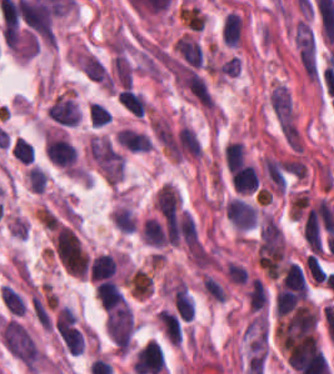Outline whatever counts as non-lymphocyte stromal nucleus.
<instances>
[{"instance_id": "obj_9", "label": "non-lymphocyte stromal nucleus", "mask_w": 334, "mask_h": 374, "mask_svg": "<svg viewBox=\"0 0 334 374\" xmlns=\"http://www.w3.org/2000/svg\"><path fill=\"white\" fill-rule=\"evenodd\" d=\"M261 163L271 192L282 196L291 169L290 162L265 155Z\"/></svg>"}, {"instance_id": "obj_7", "label": "non-lymphocyte stromal nucleus", "mask_w": 334, "mask_h": 374, "mask_svg": "<svg viewBox=\"0 0 334 374\" xmlns=\"http://www.w3.org/2000/svg\"><path fill=\"white\" fill-rule=\"evenodd\" d=\"M225 215L233 227L247 231L257 222L258 210L238 197H231L226 204Z\"/></svg>"}, {"instance_id": "obj_8", "label": "non-lymphocyte stromal nucleus", "mask_w": 334, "mask_h": 374, "mask_svg": "<svg viewBox=\"0 0 334 374\" xmlns=\"http://www.w3.org/2000/svg\"><path fill=\"white\" fill-rule=\"evenodd\" d=\"M47 114L65 126H76L81 119V109L75 98L61 93L49 104Z\"/></svg>"}, {"instance_id": "obj_10", "label": "non-lymphocyte stromal nucleus", "mask_w": 334, "mask_h": 374, "mask_svg": "<svg viewBox=\"0 0 334 374\" xmlns=\"http://www.w3.org/2000/svg\"><path fill=\"white\" fill-rule=\"evenodd\" d=\"M115 139L127 150L133 152H147L152 145L150 138L143 132L129 127H122Z\"/></svg>"}, {"instance_id": "obj_6", "label": "non-lymphocyte stromal nucleus", "mask_w": 334, "mask_h": 374, "mask_svg": "<svg viewBox=\"0 0 334 374\" xmlns=\"http://www.w3.org/2000/svg\"><path fill=\"white\" fill-rule=\"evenodd\" d=\"M105 328L117 349L129 351L134 332L131 307L123 304L111 310L107 315Z\"/></svg>"}, {"instance_id": "obj_14", "label": "non-lymphocyte stromal nucleus", "mask_w": 334, "mask_h": 374, "mask_svg": "<svg viewBox=\"0 0 334 374\" xmlns=\"http://www.w3.org/2000/svg\"><path fill=\"white\" fill-rule=\"evenodd\" d=\"M270 110L281 128L296 123L275 87L270 102Z\"/></svg>"}, {"instance_id": "obj_2", "label": "non-lymphocyte stromal nucleus", "mask_w": 334, "mask_h": 374, "mask_svg": "<svg viewBox=\"0 0 334 374\" xmlns=\"http://www.w3.org/2000/svg\"><path fill=\"white\" fill-rule=\"evenodd\" d=\"M1 340L6 350L27 367H37L42 361L36 342L18 321L2 320Z\"/></svg>"}, {"instance_id": "obj_4", "label": "non-lymphocyte stromal nucleus", "mask_w": 334, "mask_h": 374, "mask_svg": "<svg viewBox=\"0 0 334 374\" xmlns=\"http://www.w3.org/2000/svg\"><path fill=\"white\" fill-rule=\"evenodd\" d=\"M52 242L65 271L75 277H84L88 262L73 230L58 226Z\"/></svg>"}, {"instance_id": "obj_3", "label": "non-lymphocyte stromal nucleus", "mask_w": 334, "mask_h": 374, "mask_svg": "<svg viewBox=\"0 0 334 374\" xmlns=\"http://www.w3.org/2000/svg\"><path fill=\"white\" fill-rule=\"evenodd\" d=\"M88 156L106 182L118 183L123 177L124 160L106 136H91Z\"/></svg>"}, {"instance_id": "obj_1", "label": "non-lymphocyte stromal nucleus", "mask_w": 334, "mask_h": 374, "mask_svg": "<svg viewBox=\"0 0 334 374\" xmlns=\"http://www.w3.org/2000/svg\"><path fill=\"white\" fill-rule=\"evenodd\" d=\"M257 260L265 272L277 279L286 266V239L281 226L267 214L260 219Z\"/></svg>"}, {"instance_id": "obj_15", "label": "non-lymphocyte stromal nucleus", "mask_w": 334, "mask_h": 374, "mask_svg": "<svg viewBox=\"0 0 334 374\" xmlns=\"http://www.w3.org/2000/svg\"><path fill=\"white\" fill-rule=\"evenodd\" d=\"M29 188L36 193H43L48 182V175L43 168L33 166L26 171Z\"/></svg>"}, {"instance_id": "obj_5", "label": "non-lymphocyte stromal nucleus", "mask_w": 334, "mask_h": 374, "mask_svg": "<svg viewBox=\"0 0 334 374\" xmlns=\"http://www.w3.org/2000/svg\"><path fill=\"white\" fill-rule=\"evenodd\" d=\"M292 41L299 63L309 79L319 75V57L316 35L311 24L298 20L292 32Z\"/></svg>"}, {"instance_id": "obj_11", "label": "non-lymphocyte stromal nucleus", "mask_w": 334, "mask_h": 374, "mask_svg": "<svg viewBox=\"0 0 334 374\" xmlns=\"http://www.w3.org/2000/svg\"><path fill=\"white\" fill-rule=\"evenodd\" d=\"M182 199L172 182H165L156 192L155 206L162 213H176Z\"/></svg>"}, {"instance_id": "obj_12", "label": "non-lymphocyte stromal nucleus", "mask_w": 334, "mask_h": 374, "mask_svg": "<svg viewBox=\"0 0 334 374\" xmlns=\"http://www.w3.org/2000/svg\"><path fill=\"white\" fill-rule=\"evenodd\" d=\"M173 45L186 63L201 68L202 49L195 37L185 32Z\"/></svg>"}, {"instance_id": "obj_13", "label": "non-lymphocyte stromal nucleus", "mask_w": 334, "mask_h": 374, "mask_svg": "<svg viewBox=\"0 0 334 374\" xmlns=\"http://www.w3.org/2000/svg\"><path fill=\"white\" fill-rule=\"evenodd\" d=\"M111 221L121 233H133L137 227L130 208L121 205L112 211Z\"/></svg>"}]
</instances>
